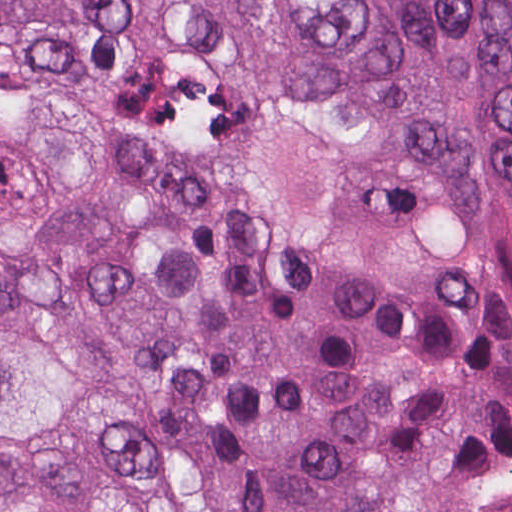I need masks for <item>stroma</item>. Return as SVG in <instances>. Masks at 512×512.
Wrapping results in <instances>:
<instances>
[{
  "label": "stroma",
  "mask_w": 512,
  "mask_h": 512,
  "mask_svg": "<svg viewBox=\"0 0 512 512\" xmlns=\"http://www.w3.org/2000/svg\"><path fill=\"white\" fill-rule=\"evenodd\" d=\"M469 512H512V449L481 476Z\"/></svg>",
  "instance_id": "35a3bbf8"
}]
</instances>
